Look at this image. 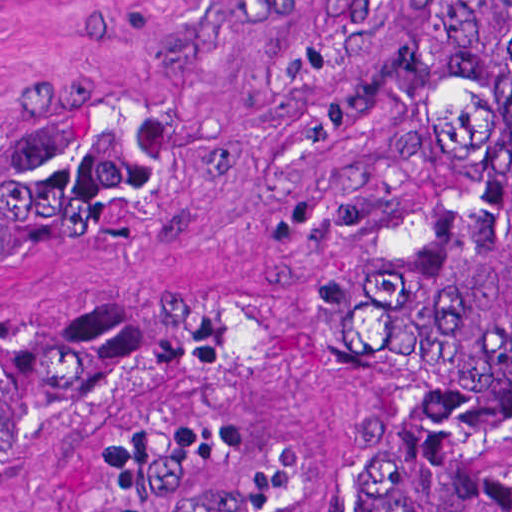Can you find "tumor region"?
<instances>
[{
	"mask_svg": "<svg viewBox=\"0 0 512 512\" xmlns=\"http://www.w3.org/2000/svg\"><path fill=\"white\" fill-rule=\"evenodd\" d=\"M136 159L69 100L0 107V280L116 215ZM132 330L0 323V431L162 355ZM512 384V0H447L405 133L368 306L360 512H489L469 463ZM146 512H269L261 447L198 431Z\"/></svg>",
	"mask_w": 512,
	"mask_h": 512,
	"instance_id": "tumor-region-1",
	"label": "tumor region"
}]
</instances>
